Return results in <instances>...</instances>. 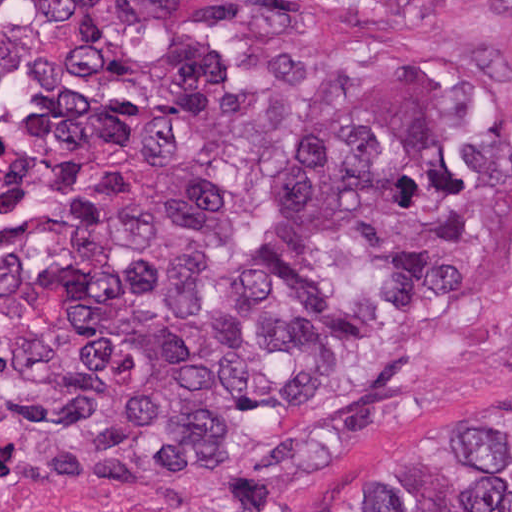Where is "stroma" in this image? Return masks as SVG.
<instances>
[{
  "label": "stroma",
  "mask_w": 512,
  "mask_h": 512,
  "mask_svg": "<svg viewBox=\"0 0 512 512\" xmlns=\"http://www.w3.org/2000/svg\"><path fill=\"white\" fill-rule=\"evenodd\" d=\"M501 2L304 0L273 34L129 17L76 38L44 31L38 0H0V264L96 217L119 195L130 139L179 51H215L261 82L350 83L399 62H443L476 80L486 121L512 135V42ZM461 265L459 297L397 317L325 393L323 402L388 358H418L413 402L386 430L286 476H187L113 512H340L395 448L472 414H512V218L480 260ZM0 496L24 512H71L27 480L16 382L1 352Z\"/></svg>",
  "instance_id": "35a3bbf8"
}]
</instances>
